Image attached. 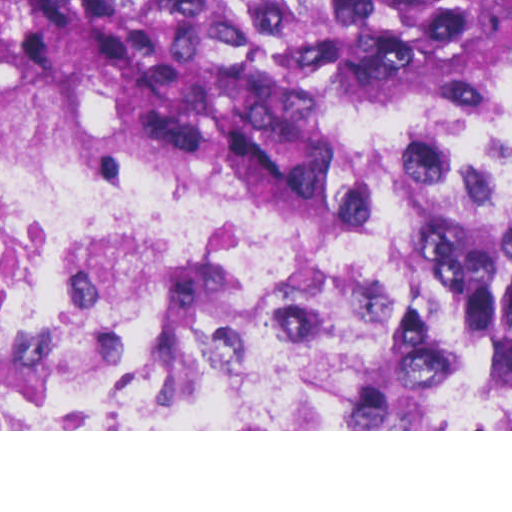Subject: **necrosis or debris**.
<instances>
[{"label":"necrosis or debris","instance_id":"4bbe7bcc","mask_svg":"<svg viewBox=\"0 0 512 512\" xmlns=\"http://www.w3.org/2000/svg\"><path fill=\"white\" fill-rule=\"evenodd\" d=\"M343 187L0 160V430L512 424V69L346 101Z\"/></svg>","mask_w":512,"mask_h":512}]
</instances>
